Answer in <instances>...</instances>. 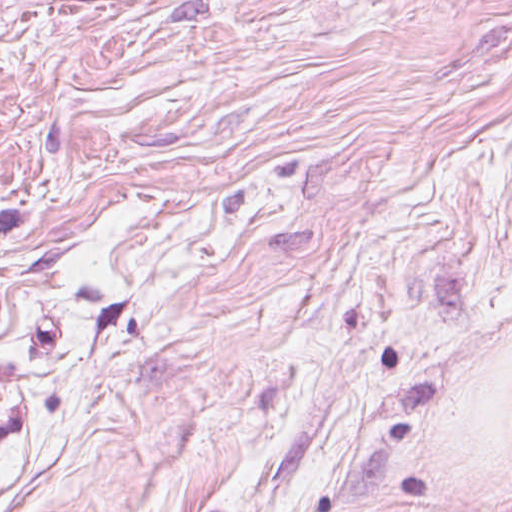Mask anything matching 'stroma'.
<instances>
[{
    "label": "stroma",
    "instance_id": "stroma-1",
    "mask_svg": "<svg viewBox=\"0 0 512 512\" xmlns=\"http://www.w3.org/2000/svg\"><path fill=\"white\" fill-rule=\"evenodd\" d=\"M0 512H512V0L0 11Z\"/></svg>",
    "mask_w": 512,
    "mask_h": 512
}]
</instances>
